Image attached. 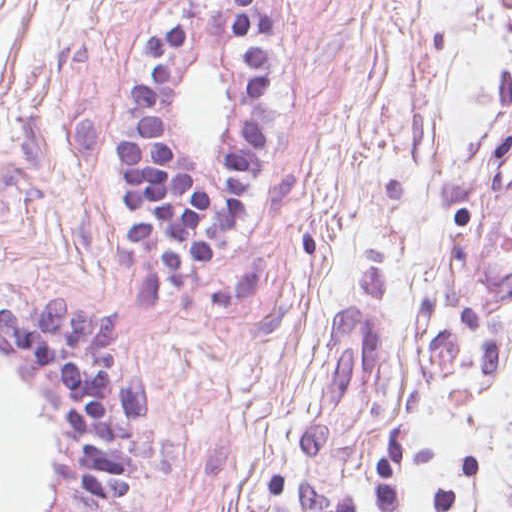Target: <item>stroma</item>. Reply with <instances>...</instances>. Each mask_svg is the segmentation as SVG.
Instances as JSON below:
<instances>
[{"mask_svg":"<svg viewBox=\"0 0 512 512\" xmlns=\"http://www.w3.org/2000/svg\"><path fill=\"white\" fill-rule=\"evenodd\" d=\"M267 158L200 290L136 249L120 145L166 23L191 36L155 98L180 168L221 184L247 67L222 0H0V301L108 314L149 382L119 512H292L302 478L357 512H512V0H260ZM229 88L201 163L176 97ZM58 434L47 370L0 348Z\"/></svg>","mask_w":512,"mask_h":512,"instance_id":"stroma-1","label":"stroma"}]
</instances>
